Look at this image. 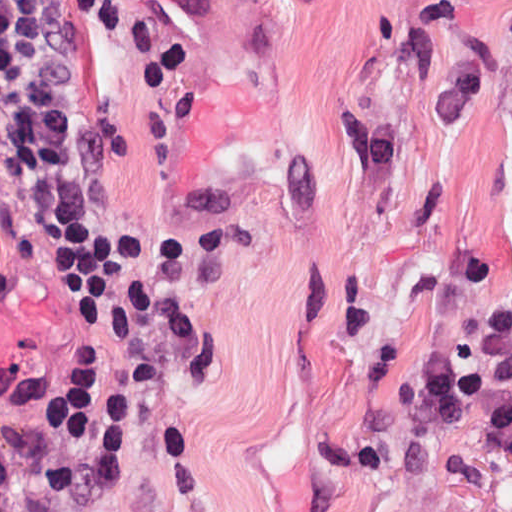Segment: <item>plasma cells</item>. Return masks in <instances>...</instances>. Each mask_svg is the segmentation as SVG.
<instances>
[{"label": "plasma cells", "mask_w": 512, "mask_h": 512, "mask_svg": "<svg viewBox=\"0 0 512 512\" xmlns=\"http://www.w3.org/2000/svg\"><path fill=\"white\" fill-rule=\"evenodd\" d=\"M504 24L512 45V6ZM402 407L416 438H441L462 420L512 462V292L473 340L450 342L414 366Z\"/></svg>", "instance_id": "plasma-cells-1"}]
</instances>
